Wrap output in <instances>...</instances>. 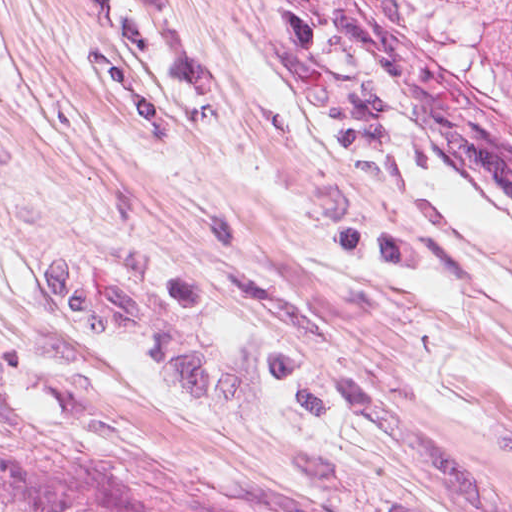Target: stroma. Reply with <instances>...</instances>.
Here are the masks:
<instances>
[{
	"instance_id": "35a3bbf8",
	"label": "stroma",
	"mask_w": 512,
	"mask_h": 512,
	"mask_svg": "<svg viewBox=\"0 0 512 512\" xmlns=\"http://www.w3.org/2000/svg\"><path fill=\"white\" fill-rule=\"evenodd\" d=\"M0 509L512 512V89L329 0H0Z\"/></svg>"
}]
</instances>
